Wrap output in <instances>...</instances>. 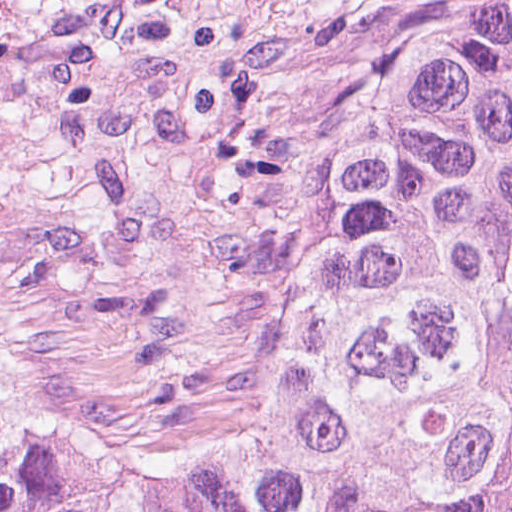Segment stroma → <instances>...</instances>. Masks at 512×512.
Masks as SVG:
<instances>
[{
    "label": "stroma",
    "mask_w": 512,
    "mask_h": 512,
    "mask_svg": "<svg viewBox=\"0 0 512 512\" xmlns=\"http://www.w3.org/2000/svg\"><path fill=\"white\" fill-rule=\"evenodd\" d=\"M486 0H22L6 162L29 364L142 425L244 420L353 95Z\"/></svg>",
    "instance_id": "stroma-1"
}]
</instances>
